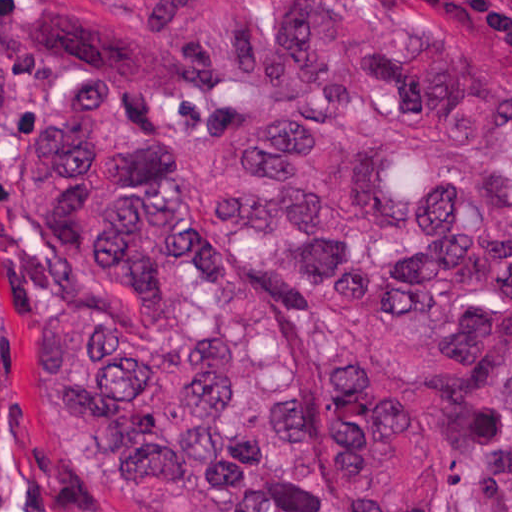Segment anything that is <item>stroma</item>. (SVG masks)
Here are the masks:
<instances>
[{"label":"stroma","instance_id":"35a3bbf8","mask_svg":"<svg viewBox=\"0 0 512 512\" xmlns=\"http://www.w3.org/2000/svg\"><path fill=\"white\" fill-rule=\"evenodd\" d=\"M463 75L512 98V0H409ZM20 4L0 0L15 26ZM143 102L162 117L178 149L181 125L226 96ZM62 238L37 213L29 154L0 124V288L6 312V425L0 438V512H108L68 443L59 401L41 359V312L61 292Z\"/></svg>","mask_w":512,"mask_h":512}]
</instances>
